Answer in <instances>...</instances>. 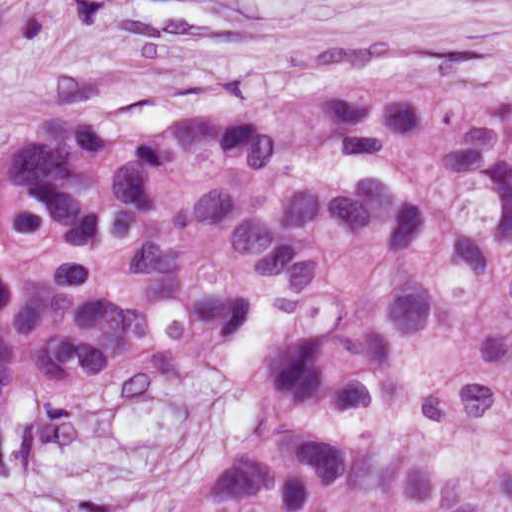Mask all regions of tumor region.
<instances>
[{
  "mask_svg": "<svg viewBox=\"0 0 512 512\" xmlns=\"http://www.w3.org/2000/svg\"><path fill=\"white\" fill-rule=\"evenodd\" d=\"M73 0L0 4V68ZM164 366L246 403L173 512H512V70L77 115L0 158V463Z\"/></svg>",
  "mask_w": 512,
  "mask_h": 512,
  "instance_id": "e687c5a6",
  "label": "tumor region"
}]
</instances>
